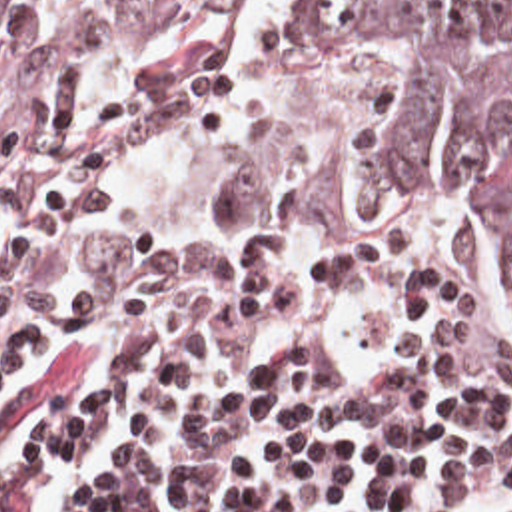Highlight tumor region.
<instances>
[{
    "label": "tumor region",
    "instance_id": "1",
    "mask_svg": "<svg viewBox=\"0 0 512 512\" xmlns=\"http://www.w3.org/2000/svg\"><path fill=\"white\" fill-rule=\"evenodd\" d=\"M244 0H0V101L138 53H266L290 133L248 173L252 201L364 211L380 183L426 179L436 213L512 255V0H294L252 31Z\"/></svg>",
    "mask_w": 512,
    "mask_h": 512
}]
</instances>
